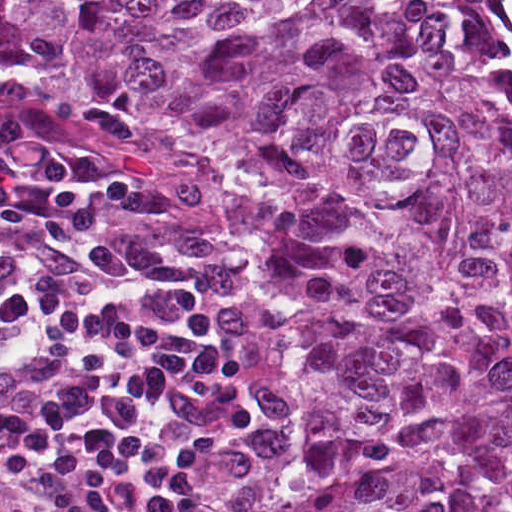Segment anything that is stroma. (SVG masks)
I'll return each instance as SVG.
<instances>
[{"label":"stroma","mask_w":512,"mask_h":512,"mask_svg":"<svg viewBox=\"0 0 512 512\" xmlns=\"http://www.w3.org/2000/svg\"><path fill=\"white\" fill-rule=\"evenodd\" d=\"M437 1L449 40L466 49L494 95L500 115L512 124V98L469 39L455 31L449 0ZM12 93H29L53 103L20 101ZM46 105H58L73 117ZM1 108L32 111L58 122L37 147L51 162L133 186L134 200L113 235L134 246L143 258L132 266L210 260L226 263L247 282L267 346V458L245 512H270L283 480L308 464L306 358L292 322V304L274 282L271 268L254 243L240 234L226 227L195 229L182 221L175 199L186 196L194 176L185 162L188 147L178 139L151 125L129 123L78 88H62L50 78L15 75L0 58ZM98 156L140 180L150 192Z\"/></svg>","instance_id":"35a3bbf8"}]
</instances>
